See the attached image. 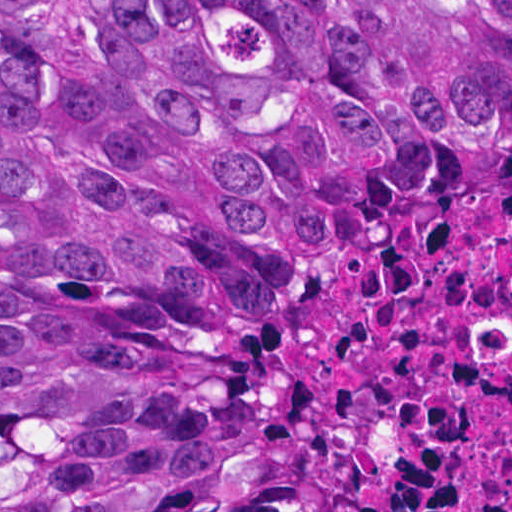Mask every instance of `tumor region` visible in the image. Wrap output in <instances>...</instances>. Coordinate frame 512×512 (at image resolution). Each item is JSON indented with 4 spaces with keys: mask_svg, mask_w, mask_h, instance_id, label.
<instances>
[{
    "mask_svg": "<svg viewBox=\"0 0 512 512\" xmlns=\"http://www.w3.org/2000/svg\"><path fill=\"white\" fill-rule=\"evenodd\" d=\"M317 178L512 186V0H0V512H377L262 365Z\"/></svg>",
    "mask_w": 512,
    "mask_h": 512,
    "instance_id": "e687c5a6",
    "label": "tumor region"
}]
</instances>
